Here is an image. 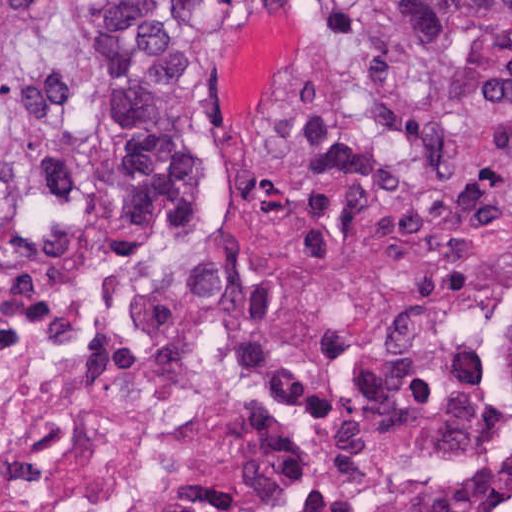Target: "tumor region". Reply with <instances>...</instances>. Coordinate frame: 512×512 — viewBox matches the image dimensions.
I'll return each mask as SVG.
<instances>
[{
  "mask_svg": "<svg viewBox=\"0 0 512 512\" xmlns=\"http://www.w3.org/2000/svg\"><path fill=\"white\" fill-rule=\"evenodd\" d=\"M216 0H0V186L227 289L184 67ZM246 211L275 251L512 219V0H337L303 32Z\"/></svg>",
  "mask_w": 512,
  "mask_h": 512,
  "instance_id": "obj_1",
  "label": "tumor region"
}]
</instances>
